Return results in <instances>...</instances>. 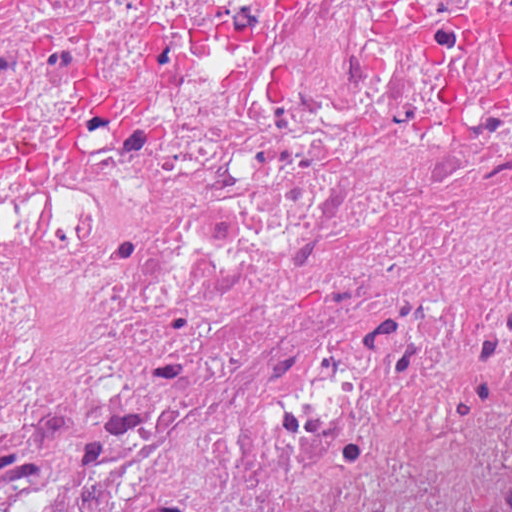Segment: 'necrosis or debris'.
<instances>
[{"label":"necrosis or debris","instance_id":"4bbe7bcc","mask_svg":"<svg viewBox=\"0 0 512 512\" xmlns=\"http://www.w3.org/2000/svg\"><path fill=\"white\" fill-rule=\"evenodd\" d=\"M0 512H512V0H0Z\"/></svg>","mask_w":512,"mask_h":512}]
</instances>
